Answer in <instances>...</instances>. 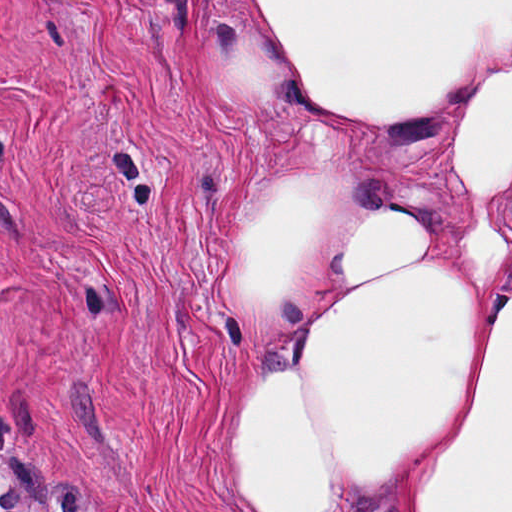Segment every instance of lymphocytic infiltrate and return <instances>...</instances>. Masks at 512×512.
<instances>
[{"label":"lymphocytic infiltrate","instance_id":"f902f5d3","mask_svg":"<svg viewBox=\"0 0 512 512\" xmlns=\"http://www.w3.org/2000/svg\"><path fill=\"white\" fill-rule=\"evenodd\" d=\"M0 496V512H29L23 507V495L19 492L18 486L11 484L4 488Z\"/></svg>","mask_w":512,"mask_h":512}]
</instances>
